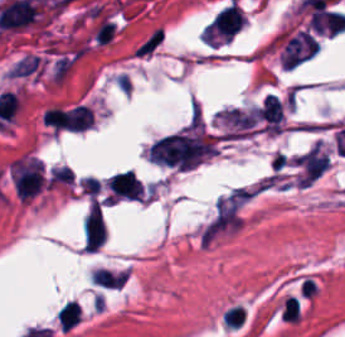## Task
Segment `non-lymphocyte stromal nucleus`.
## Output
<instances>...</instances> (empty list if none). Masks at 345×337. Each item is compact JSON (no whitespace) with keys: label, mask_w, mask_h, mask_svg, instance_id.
<instances>
[{"label":"non-lymphocyte stromal nucleus","mask_w":345,"mask_h":337,"mask_svg":"<svg viewBox=\"0 0 345 337\" xmlns=\"http://www.w3.org/2000/svg\"><path fill=\"white\" fill-rule=\"evenodd\" d=\"M163 40L164 33L158 25L134 47V54L139 58H147L156 52Z\"/></svg>","instance_id":"non-lymphocyte-stromal-nucleus-4"},{"label":"non-lymphocyte stromal nucleus","mask_w":345,"mask_h":337,"mask_svg":"<svg viewBox=\"0 0 345 337\" xmlns=\"http://www.w3.org/2000/svg\"><path fill=\"white\" fill-rule=\"evenodd\" d=\"M215 150V139L202 129H182L158 138L149 148L150 158L162 165L190 168Z\"/></svg>","instance_id":"non-lymphocyte-stromal-nucleus-1"},{"label":"non-lymphocyte stromal nucleus","mask_w":345,"mask_h":337,"mask_svg":"<svg viewBox=\"0 0 345 337\" xmlns=\"http://www.w3.org/2000/svg\"><path fill=\"white\" fill-rule=\"evenodd\" d=\"M246 187L236 185L214 201L201 231L200 240L212 241L236 230L243 219Z\"/></svg>","instance_id":"non-lymphocyte-stromal-nucleus-2"},{"label":"non-lymphocyte stromal nucleus","mask_w":345,"mask_h":337,"mask_svg":"<svg viewBox=\"0 0 345 337\" xmlns=\"http://www.w3.org/2000/svg\"><path fill=\"white\" fill-rule=\"evenodd\" d=\"M85 248L98 250L106 237V226L99 205H91L84 222Z\"/></svg>","instance_id":"non-lymphocyte-stromal-nucleus-3"}]
</instances>
